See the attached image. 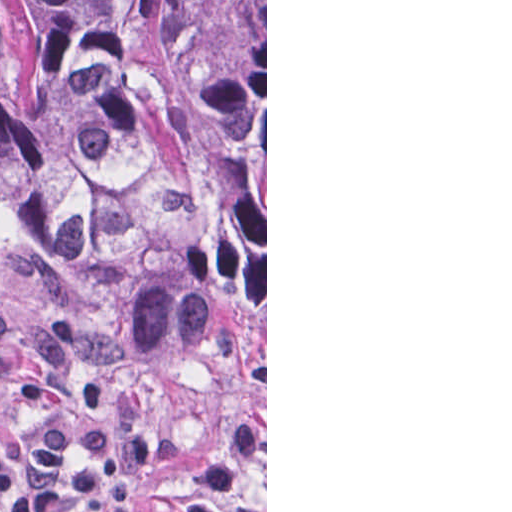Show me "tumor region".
<instances>
[{"label":"tumor region","instance_id":"1","mask_svg":"<svg viewBox=\"0 0 512 512\" xmlns=\"http://www.w3.org/2000/svg\"><path fill=\"white\" fill-rule=\"evenodd\" d=\"M0 219L150 365L265 356V0H0Z\"/></svg>","mask_w":512,"mask_h":512}]
</instances>
